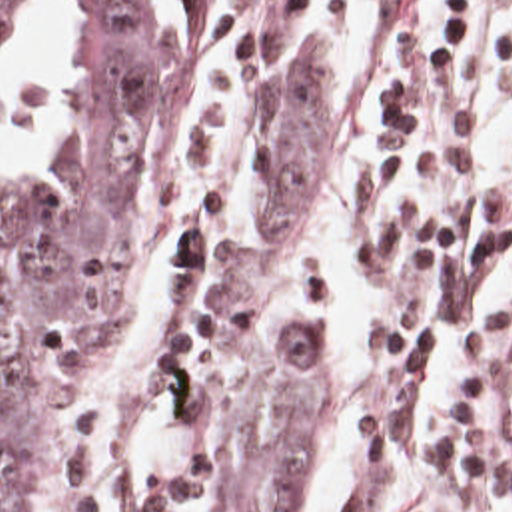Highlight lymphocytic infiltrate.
Wrapping results in <instances>:
<instances>
[{
	"mask_svg": "<svg viewBox=\"0 0 512 512\" xmlns=\"http://www.w3.org/2000/svg\"><path fill=\"white\" fill-rule=\"evenodd\" d=\"M489 0H389L365 74L379 94V144L359 210L393 180L431 184L383 234L355 250L375 310L371 350L397 368L431 364L455 334L511 234L512 196L487 168L483 88L465 74L461 38ZM355 0H315V50ZM512 344V300L471 338L439 423L411 405L365 415L335 512H493L512 497V453L495 421V389Z\"/></svg>",
	"mask_w": 512,
	"mask_h": 512,
	"instance_id": "f902f5d3",
	"label": "lymphocytic infiltrate"
}]
</instances>
